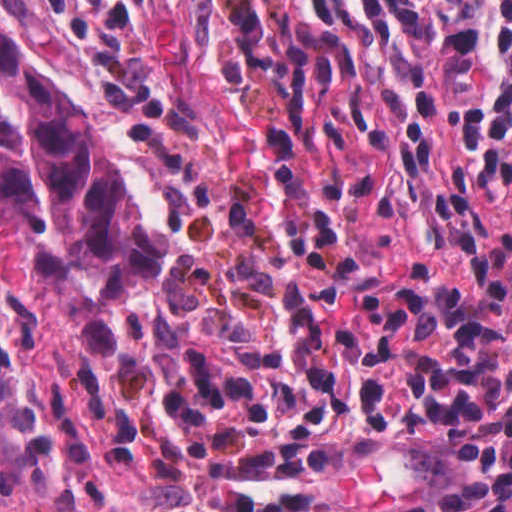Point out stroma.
Masks as SVG:
<instances>
[{"mask_svg": "<svg viewBox=\"0 0 512 512\" xmlns=\"http://www.w3.org/2000/svg\"><path fill=\"white\" fill-rule=\"evenodd\" d=\"M89 71L31 66L94 125L164 234L159 273L105 311L93 352L0 224V512H34L161 439L173 370L213 346L309 354L433 281L392 153L359 110L274 90L243 0H44Z\"/></svg>", "mask_w": 512, "mask_h": 512, "instance_id": "35a3bbf8", "label": "stroma"}]
</instances>
